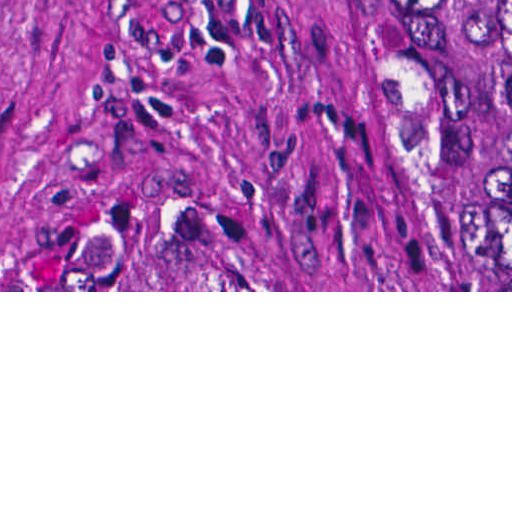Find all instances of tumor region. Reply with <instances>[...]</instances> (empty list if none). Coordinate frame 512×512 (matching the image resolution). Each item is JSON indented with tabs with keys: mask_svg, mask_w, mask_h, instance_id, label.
<instances>
[{
	"mask_svg": "<svg viewBox=\"0 0 512 512\" xmlns=\"http://www.w3.org/2000/svg\"><path fill=\"white\" fill-rule=\"evenodd\" d=\"M446 77L450 113H512V0H403ZM203 222L109 231L43 278L2 290H244L199 249ZM463 262L479 291H512V128L478 147L466 190Z\"/></svg>",
	"mask_w": 512,
	"mask_h": 512,
	"instance_id": "e687c5a6",
	"label": "tumor region"
}]
</instances>
